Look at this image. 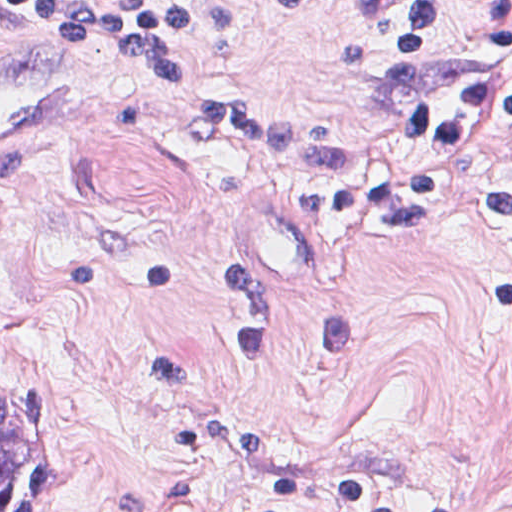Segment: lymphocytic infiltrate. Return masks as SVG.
I'll return each mask as SVG.
<instances>
[{
  "instance_id": "obj_1",
  "label": "lymphocytic infiltrate",
  "mask_w": 512,
  "mask_h": 512,
  "mask_svg": "<svg viewBox=\"0 0 512 512\" xmlns=\"http://www.w3.org/2000/svg\"><path fill=\"white\" fill-rule=\"evenodd\" d=\"M228 1H0V51L25 25L55 23L165 80L199 139L299 169L324 236L433 242L477 223L512 238V172L468 170L479 140L512 132V1H353L337 57L382 110L391 145L328 141L312 112L205 72V37ZM147 387L201 465L243 494L317 512H474L452 496L332 465L232 407L181 347L148 342Z\"/></svg>"
}]
</instances>
